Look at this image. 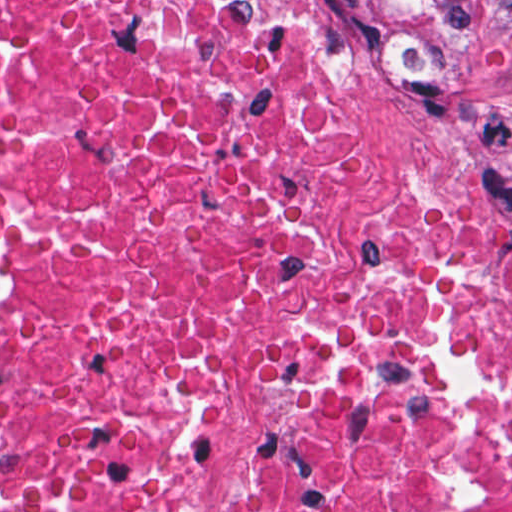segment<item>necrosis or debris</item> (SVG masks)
I'll use <instances>...</instances> for the list:
<instances>
[{
	"mask_svg": "<svg viewBox=\"0 0 512 512\" xmlns=\"http://www.w3.org/2000/svg\"><path fill=\"white\" fill-rule=\"evenodd\" d=\"M0 512H512V244L294 0H0Z\"/></svg>",
	"mask_w": 512,
	"mask_h": 512,
	"instance_id": "obj_1",
	"label": "necrosis or debris"
}]
</instances>
